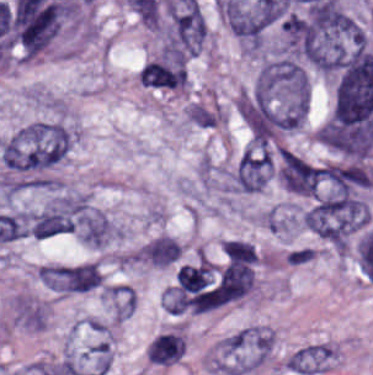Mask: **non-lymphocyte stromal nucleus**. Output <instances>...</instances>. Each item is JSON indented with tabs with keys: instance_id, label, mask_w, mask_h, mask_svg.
I'll return each mask as SVG.
<instances>
[{
	"instance_id": "1",
	"label": "non-lymphocyte stromal nucleus",
	"mask_w": 373,
	"mask_h": 375,
	"mask_svg": "<svg viewBox=\"0 0 373 375\" xmlns=\"http://www.w3.org/2000/svg\"><path fill=\"white\" fill-rule=\"evenodd\" d=\"M73 131L67 123L32 120L15 129L1 144L10 181L40 179L68 152Z\"/></svg>"
},
{
	"instance_id": "2",
	"label": "non-lymphocyte stromal nucleus",
	"mask_w": 373,
	"mask_h": 375,
	"mask_svg": "<svg viewBox=\"0 0 373 375\" xmlns=\"http://www.w3.org/2000/svg\"><path fill=\"white\" fill-rule=\"evenodd\" d=\"M273 173V151L265 143L251 142L238 156L227 180L230 191L256 192Z\"/></svg>"
},
{
	"instance_id": "3",
	"label": "non-lymphocyte stromal nucleus",
	"mask_w": 373,
	"mask_h": 375,
	"mask_svg": "<svg viewBox=\"0 0 373 375\" xmlns=\"http://www.w3.org/2000/svg\"><path fill=\"white\" fill-rule=\"evenodd\" d=\"M240 109L252 137L277 139L286 129L283 112L254 85L240 91Z\"/></svg>"
},
{
	"instance_id": "4",
	"label": "non-lymphocyte stromal nucleus",
	"mask_w": 373,
	"mask_h": 375,
	"mask_svg": "<svg viewBox=\"0 0 373 375\" xmlns=\"http://www.w3.org/2000/svg\"><path fill=\"white\" fill-rule=\"evenodd\" d=\"M278 175L287 190L299 195H319L323 168L300 154L280 149Z\"/></svg>"
},
{
	"instance_id": "5",
	"label": "non-lymphocyte stromal nucleus",
	"mask_w": 373,
	"mask_h": 375,
	"mask_svg": "<svg viewBox=\"0 0 373 375\" xmlns=\"http://www.w3.org/2000/svg\"><path fill=\"white\" fill-rule=\"evenodd\" d=\"M147 87L163 90L183 89L188 82L186 60L162 51L145 63Z\"/></svg>"
},
{
	"instance_id": "6",
	"label": "non-lymphocyte stromal nucleus",
	"mask_w": 373,
	"mask_h": 375,
	"mask_svg": "<svg viewBox=\"0 0 373 375\" xmlns=\"http://www.w3.org/2000/svg\"><path fill=\"white\" fill-rule=\"evenodd\" d=\"M182 252L179 241L167 234L148 239L135 252L136 263L158 267L174 266Z\"/></svg>"
},
{
	"instance_id": "7",
	"label": "non-lymphocyte stromal nucleus",
	"mask_w": 373,
	"mask_h": 375,
	"mask_svg": "<svg viewBox=\"0 0 373 375\" xmlns=\"http://www.w3.org/2000/svg\"><path fill=\"white\" fill-rule=\"evenodd\" d=\"M103 280V273L95 262L66 265L62 269L63 290H91Z\"/></svg>"
},
{
	"instance_id": "8",
	"label": "non-lymphocyte stromal nucleus",
	"mask_w": 373,
	"mask_h": 375,
	"mask_svg": "<svg viewBox=\"0 0 373 375\" xmlns=\"http://www.w3.org/2000/svg\"><path fill=\"white\" fill-rule=\"evenodd\" d=\"M185 339L177 332H163L156 336L146 348L150 361L170 364L184 354Z\"/></svg>"
},
{
	"instance_id": "9",
	"label": "non-lymphocyte stromal nucleus",
	"mask_w": 373,
	"mask_h": 375,
	"mask_svg": "<svg viewBox=\"0 0 373 375\" xmlns=\"http://www.w3.org/2000/svg\"><path fill=\"white\" fill-rule=\"evenodd\" d=\"M214 264L209 260H199L179 266L178 286L185 292L204 290L212 281Z\"/></svg>"
},
{
	"instance_id": "10",
	"label": "non-lymphocyte stromal nucleus",
	"mask_w": 373,
	"mask_h": 375,
	"mask_svg": "<svg viewBox=\"0 0 373 375\" xmlns=\"http://www.w3.org/2000/svg\"><path fill=\"white\" fill-rule=\"evenodd\" d=\"M103 295L115 318H125L133 307L131 286L106 284Z\"/></svg>"
},
{
	"instance_id": "11",
	"label": "non-lymphocyte stromal nucleus",
	"mask_w": 373,
	"mask_h": 375,
	"mask_svg": "<svg viewBox=\"0 0 373 375\" xmlns=\"http://www.w3.org/2000/svg\"><path fill=\"white\" fill-rule=\"evenodd\" d=\"M254 283L251 266L244 263L229 265V301L240 298L247 293Z\"/></svg>"
},
{
	"instance_id": "12",
	"label": "non-lymphocyte stromal nucleus",
	"mask_w": 373,
	"mask_h": 375,
	"mask_svg": "<svg viewBox=\"0 0 373 375\" xmlns=\"http://www.w3.org/2000/svg\"><path fill=\"white\" fill-rule=\"evenodd\" d=\"M222 245L232 260L253 264L257 260L255 246L251 241L235 238L224 239Z\"/></svg>"
},
{
	"instance_id": "13",
	"label": "non-lymphocyte stromal nucleus",
	"mask_w": 373,
	"mask_h": 375,
	"mask_svg": "<svg viewBox=\"0 0 373 375\" xmlns=\"http://www.w3.org/2000/svg\"><path fill=\"white\" fill-rule=\"evenodd\" d=\"M162 304L169 313H179L186 308L188 296L175 285H168L162 292Z\"/></svg>"
}]
</instances>
